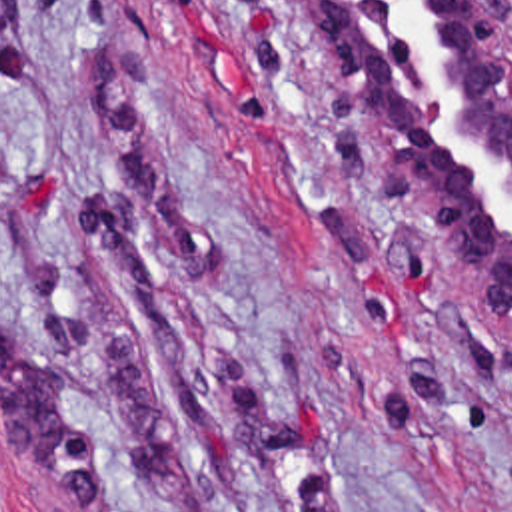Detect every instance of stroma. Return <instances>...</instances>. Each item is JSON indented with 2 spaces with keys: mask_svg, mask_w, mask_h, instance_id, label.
Instances as JSON below:
<instances>
[{
  "mask_svg": "<svg viewBox=\"0 0 512 512\" xmlns=\"http://www.w3.org/2000/svg\"><path fill=\"white\" fill-rule=\"evenodd\" d=\"M0 512H512V320L284 0H0Z\"/></svg>",
  "mask_w": 512,
  "mask_h": 512,
  "instance_id": "stroma-1",
  "label": "stroma"
}]
</instances>
